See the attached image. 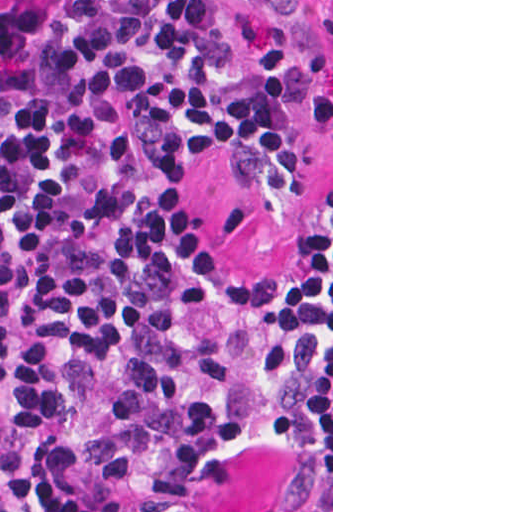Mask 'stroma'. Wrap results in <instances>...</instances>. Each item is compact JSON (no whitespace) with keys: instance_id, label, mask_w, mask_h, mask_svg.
<instances>
[{"instance_id":"35a3bbf8","label":"stroma","mask_w":512,"mask_h":512,"mask_svg":"<svg viewBox=\"0 0 512 512\" xmlns=\"http://www.w3.org/2000/svg\"><path fill=\"white\" fill-rule=\"evenodd\" d=\"M233 25L226 55L272 75L290 94L304 200L282 211L251 179L248 165L220 152L204 167L198 216L210 244L243 276L293 279L303 252L331 209V362L325 370L278 381L260 398L277 430L223 473L217 512H272L304 458L331 479L333 512V0H224Z\"/></svg>"}]
</instances>
